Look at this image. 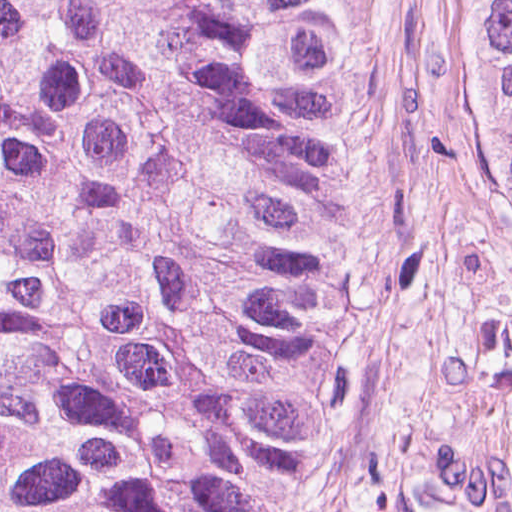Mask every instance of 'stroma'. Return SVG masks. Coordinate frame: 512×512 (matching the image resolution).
I'll use <instances>...</instances> for the list:
<instances>
[{"mask_svg":"<svg viewBox=\"0 0 512 512\" xmlns=\"http://www.w3.org/2000/svg\"><path fill=\"white\" fill-rule=\"evenodd\" d=\"M361 73V197L287 512L512 502V159L482 0H332Z\"/></svg>","mask_w":512,"mask_h":512,"instance_id":"stroma-1","label":"stroma"}]
</instances>
